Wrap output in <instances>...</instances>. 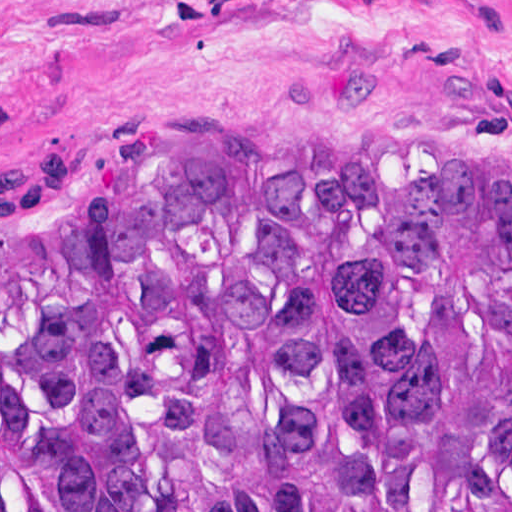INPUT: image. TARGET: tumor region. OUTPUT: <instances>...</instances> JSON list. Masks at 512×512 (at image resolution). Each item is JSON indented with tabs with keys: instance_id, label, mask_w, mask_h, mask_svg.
I'll return each mask as SVG.
<instances>
[{
	"instance_id": "tumor-region-1",
	"label": "tumor region",
	"mask_w": 512,
	"mask_h": 512,
	"mask_svg": "<svg viewBox=\"0 0 512 512\" xmlns=\"http://www.w3.org/2000/svg\"><path fill=\"white\" fill-rule=\"evenodd\" d=\"M0 512H512V174L0 181Z\"/></svg>"
}]
</instances>
